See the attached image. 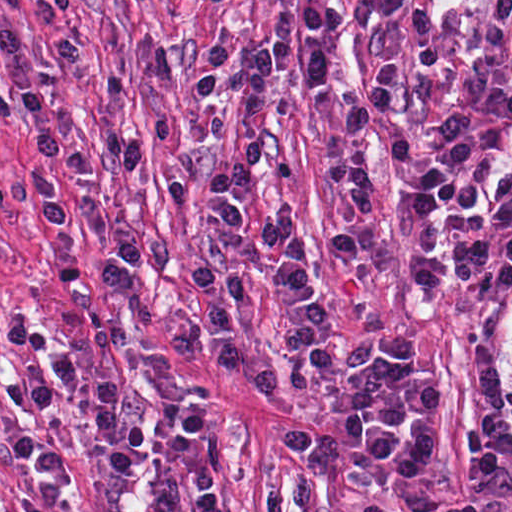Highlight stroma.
Instances as JSON below:
<instances>
[{
  "instance_id": "1",
  "label": "stroma",
  "mask_w": 512,
  "mask_h": 512,
  "mask_svg": "<svg viewBox=\"0 0 512 512\" xmlns=\"http://www.w3.org/2000/svg\"><path fill=\"white\" fill-rule=\"evenodd\" d=\"M489 0H413L395 54L403 80L377 133L358 151L335 135V108L368 69V55L342 0H0V20L24 33L35 82L60 143L90 168L52 176L71 230L81 276L99 269L121 239L137 245L128 291L61 286L52 239L29 201L5 202L0 223V383L32 361L5 333L27 320L73 354L89 376L123 379L134 414L158 397H192L221 440L227 512H264L270 475L290 461L267 393L206 360L173 354L168 328L198 309L193 267L250 277L262 301L242 322L257 351L282 374L291 412L310 433L334 436V375L304 395L310 369L282 346L288 309L270 285L236 261L207 257L211 230L200 203L207 183L239 157L233 82L265 45L317 37L335 69L312 86L295 58L278 67L271 106L254 140L262 161L242 203L258 229L291 207L305 259L340 339V362L358 329L403 331L408 361L434 377L426 483H405L383 461L357 451L325 477L315 512H510L512 485L469 479L458 451L470 420L465 338L491 341L502 382L512 363V281L488 315L440 314L402 287L384 230L387 166L417 134L454 78L456 49ZM0 172L26 181L36 167L25 148L23 113L0 60ZM29 417L0 387V512H24L36 473L17 460L13 432ZM55 437L69 476L55 512H159L158 484L180 465L181 430L164 429L125 481L101 462L86 406L74 391L55 404ZM173 512H193L185 505Z\"/></svg>"
}]
</instances>
